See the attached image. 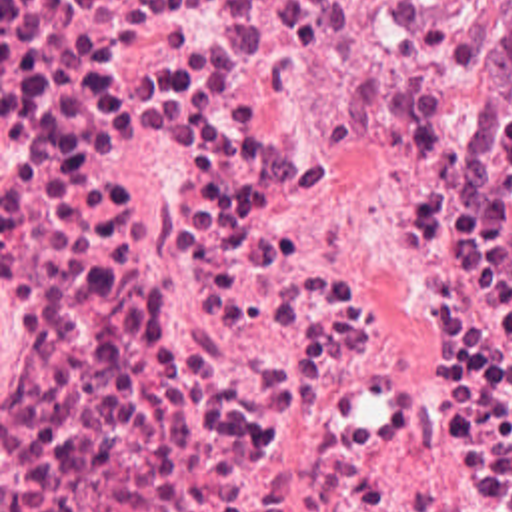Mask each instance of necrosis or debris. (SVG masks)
I'll use <instances>...</instances> for the list:
<instances>
[{
  "instance_id": "necrosis-or-debris-1",
  "label": "necrosis or debris",
  "mask_w": 512,
  "mask_h": 512,
  "mask_svg": "<svg viewBox=\"0 0 512 512\" xmlns=\"http://www.w3.org/2000/svg\"><path fill=\"white\" fill-rule=\"evenodd\" d=\"M468 7L0 0V512H512Z\"/></svg>"
}]
</instances>
